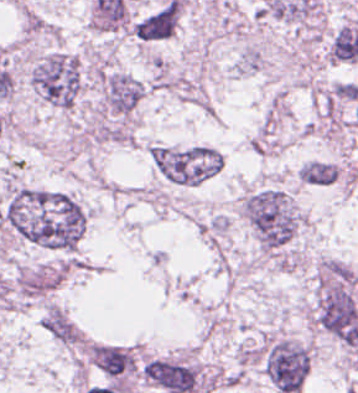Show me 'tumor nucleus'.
<instances>
[{"instance_id":"obj_11","label":"tumor nucleus","mask_w":358,"mask_h":393,"mask_svg":"<svg viewBox=\"0 0 358 393\" xmlns=\"http://www.w3.org/2000/svg\"><path fill=\"white\" fill-rule=\"evenodd\" d=\"M302 180L312 185H327L335 180L338 170L335 163L314 159L303 163L298 169Z\"/></svg>"},{"instance_id":"obj_7","label":"tumor nucleus","mask_w":358,"mask_h":393,"mask_svg":"<svg viewBox=\"0 0 358 393\" xmlns=\"http://www.w3.org/2000/svg\"><path fill=\"white\" fill-rule=\"evenodd\" d=\"M141 95V82L119 72L105 73L102 82L103 103L108 112L126 115L135 108Z\"/></svg>"},{"instance_id":"obj_9","label":"tumor nucleus","mask_w":358,"mask_h":393,"mask_svg":"<svg viewBox=\"0 0 358 393\" xmlns=\"http://www.w3.org/2000/svg\"><path fill=\"white\" fill-rule=\"evenodd\" d=\"M40 326L52 339L64 345L75 346L82 342L78 327L57 305L47 304L40 318Z\"/></svg>"},{"instance_id":"obj_10","label":"tumor nucleus","mask_w":358,"mask_h":393,"mask_svg":"<svg viewBox=\"0 0 358 393\" xmlns=\"http://www.w3.org/2000/svg\"><path fill=\"white\" fill-rule=\"evenodd\" d=\"M329 61H353L358 57V28L342 24L337 28L326 51Z\"/></svg>"},{"instance_id":"obj_4","label":"tumor nucleus","mask_w":358,"mask_h":393,"mask_svg":"<svg viewBox=\"0 0 358 393\" xmlns=\"http://www.w3.org/2000/svg\"><path fill=\"white\" fill-rule=\"evenodd\" d=\"M148 152L155 170L177 184H196L219 168V152L212 145L151 144Z\"/></svg>"},{"instance_id":"obj_3","label":"tumor nucleus","mask_w":358,"mask_h":393,"mask_svg":"<svg viewBox=\"0 0 358 393\" xmlns=\"http://www.w3.org/2000/svg\"><path fill=\"white\" fill-rule=\"evenodd\" d=\"M32 90L53 107L72 108L82 83L75 55L50 51L38 57L29 72Z\"/></svg>"},{"instance_id":"obj_2","label":"tumor nucleus","mask_w":358,"mask_h":393,"mask_svg":"<svg viewBox=\"0 0 358 393\" xmlns=\"http://www.w3.org/2000/svg\"><path fill=\"white\" fill-rule=\"evenodd\" d=\"M241 215L254 241L264 251L283 245L299 222L288 196L274 188L252 190L242 199Z\"/></svg>"},{"instance_id":"obj_1","label":"tumor nucleus","mask_w":358,"mask_h":393,"mask_svg":"<svg viewBox=\"0 0 358 393\" xmlns=\"http://www.w3.org/2000/svg\"><path fill=\"white\" fill-rule=\"evenodd\" d=\"M0 222L25 242L72 252L84 228V211L62 191L16 185Z\"/></svg>"},{"instance_id":"obj_6","label":"tumor nucleus","mask_w":358,"mask_h":393,"mask_svg":"<svg viewBox=\"0 0 358 393\" xmlns=\"http://www.w3.org/2000/svg\"><path fill=\"white\" fill-rule=\"evenodd\" d=\"M88 361L114 381L132 374L136 367V355L129 345L93 343L88 351Z\"/></svg>"},{"instance_id":"obj_8","label":"tumor nucleus","mask_w":358,"mask_h":393,"mask_svg":"<svg viewBox=\"0 0 358 393\" xmlns=\"http://www.w3.org/2000/svg\"><path fill=\"white\" fill-rule=\"evenodd\" d=\"M178 23V3L167 0L139 18L131 29L138 40L157 41L172 35Z\"/></svg>"},{"instance_id":"obj_5","label":"tumor nucleus","mask_w":358,"mask_h":393,"mask_svg":"<svg viewBox=\"0 0 358 393\" xmlns=\"http://www.w3.org/2000/svg\"><path fill=\"white\" fill-rule=\"evenodd\" d=\"M309 364V347L285 337L270 338L260 352V367L278 393H297Z\"/></svg>"}]
</instances>
